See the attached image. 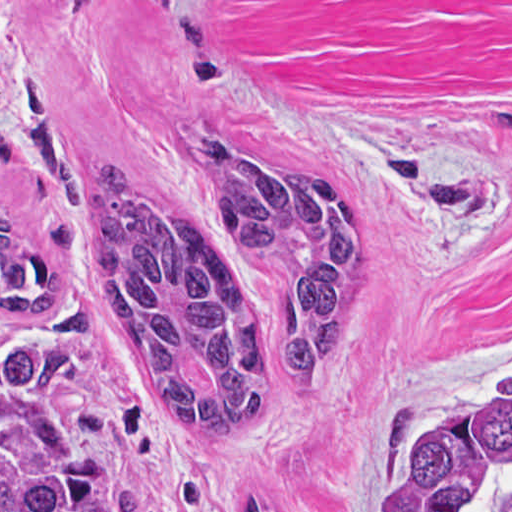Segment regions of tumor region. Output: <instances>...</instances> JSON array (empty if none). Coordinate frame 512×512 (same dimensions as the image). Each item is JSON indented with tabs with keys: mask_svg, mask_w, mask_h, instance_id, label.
Listing matches in <instances>:
<instances>
[{
	"mask_svg": "<svg viewBox=\"0 0 512 512\" xmlns=\"http://www.w3.org/2000/svg\"><path fill=\"white\" fill-rule=\"evenodd\" d=\"M38 187L92 205L88 354L37 326L0 336V512H108L128 404L193 441L237 430L318 352L365 278L368 200L333 177L258 171L194 137L186 192L162 198L105 160L83 169L35 81L13 93ZM65 270L0 207V319H49ZM216 512H316L274 487ZM367 512H512V386L415 439Z\"/></svg>",
	"mask_w": 512,
	"mask_h": 512,
	"instance_id": "e687c5a6",
	"label": "tumor region"
}]
</instances>
